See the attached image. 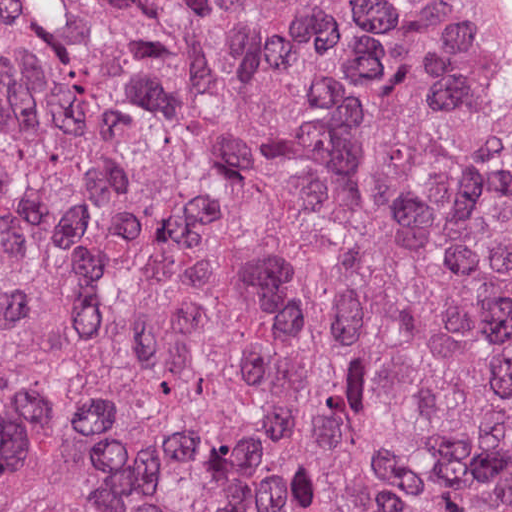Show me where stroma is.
I'll use <instances>...</instances> for the list:
<instances>
[{
  "label": "stroma",
  "mask_w": 512,
  "mask_h": 512,
  "mask_svg": "<svg viewBox=\"0 0 512 512\" xmlns=\"http://www.w3.org/2000/svg\"><path fill=\"white\" fill-rule=\"evenodd\" d=\"M489 34L512 50V0H465ZM496 139L512 149V108L478 119Z\"/></svg>",
  "instance_id": "obj_1"
}]
</instances>
